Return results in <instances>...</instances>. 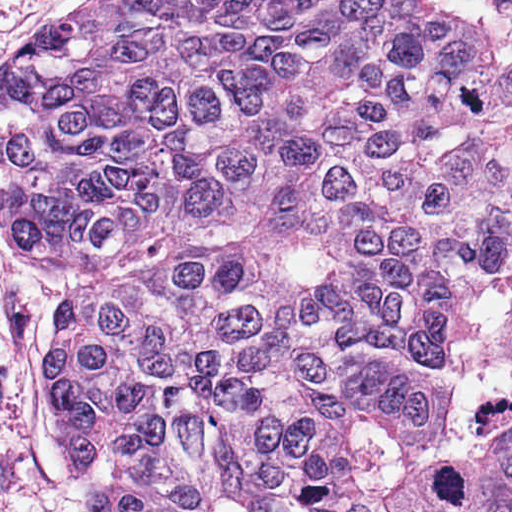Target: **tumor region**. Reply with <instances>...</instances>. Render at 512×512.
<instances>
[{
    "instance_id": "e687c5a6",
    "label": "tumor region",
    "mask_w": 512,
    "mask_h": 512,
    "mask_svg": "<svg viewBox=\"0 0 512 512\" xmlns=\"http://www.w3.org/2000/svg\"><path fill=\"white\" fill-rule=\"evenodd\" d=\"M512 328V0H366Z\"/></svg>"
}]
</instances>
